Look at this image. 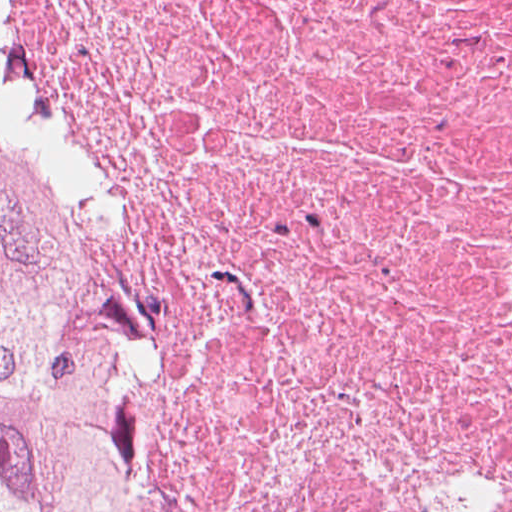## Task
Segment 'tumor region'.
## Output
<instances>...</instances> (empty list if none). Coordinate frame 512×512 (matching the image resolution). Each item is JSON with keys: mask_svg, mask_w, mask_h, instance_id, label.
<instances>
[{"mask_svg": "<svg viewBox=\"0 0 512 512\" xmlns=\"http://www.w3.org/2000/svg\"><path fill=\"white\" fill-rule=\"evenodd\" d=\"M123 415L85 266L0 116V512H125Z\"/></svg>", "mask_w": 512, "mask_h": 512, "instance_id": "1", "label": "tumor region"}]
</instances>
